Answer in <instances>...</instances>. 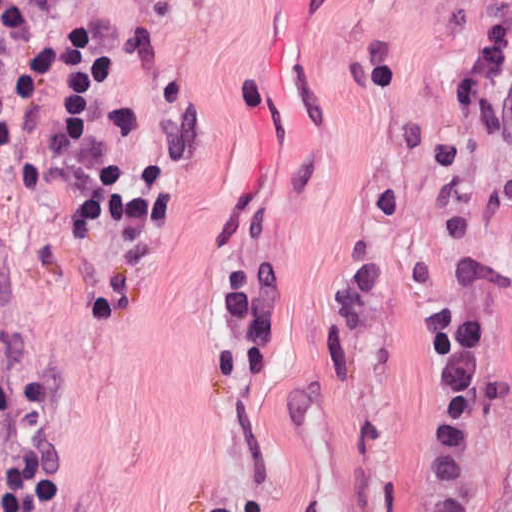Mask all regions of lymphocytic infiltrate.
<instances>
[{"label":"lymphocytic infiltrate","mask_w":512,"mask_h":512,"mask_svg":"<svg viewBox=\"0 0 512 512\" xmlns=\"http://www.w3.org/2000/svg\"><path fill=\"white\" fill-rule=\"evenodd\" d=\"M0 161L8 182L51 199L91 169L86 46L63 0H0ZM45 370L0 352V512H46L51 397ZM212 512H269L223 503Z\"/></svg>","instance_id":"1"}]
</instances>
